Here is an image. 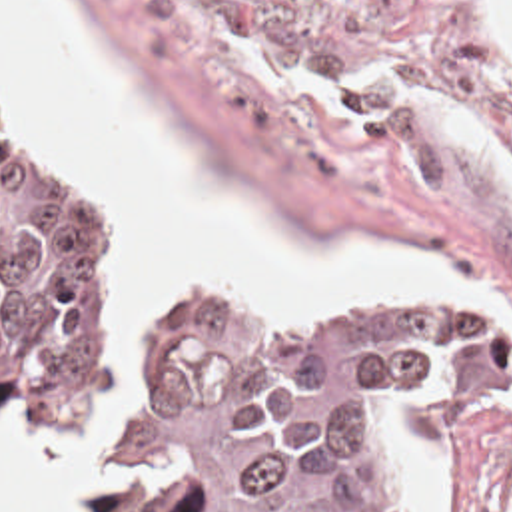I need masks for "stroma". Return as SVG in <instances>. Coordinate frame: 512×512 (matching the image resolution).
Listing matches in <instances>:
<instances>
[{
    "label": "stroma",
    "instance_id": "35a3bbf8",
    "mask_svg": "<svg viewBox=\"0 0 512 512\" xmlns=\"http://www.w3.org/2000/svg\"><path fill=\"white\" fill-rule=\"evenodd\" d=\"M102 47L174 161L225 201L263 207L315 255L423 253L512 309V45L477 0H48ZM0 145L66 167L130 249L100 171L10 137ZM182 297L211 303L253 337H311L405 303L471 307L512 345V323L477 295L391 293L351 311L259 327L215 277L174 291L150 329L140 387L120 431L118 331L100 443L124 451L162 329ZM124 309V303H122ZM122 319V315H120ZM120 329V325H118ZM16 443L94 463L72 443L2 427ZM369 481L389 512H512V399L419 445L377 423Z\"/></svg>",
    "mask_w": 512,
    "mask_h": 512
}]
</instances>
